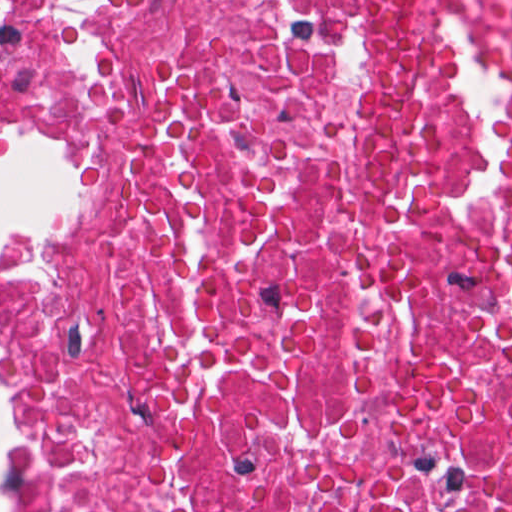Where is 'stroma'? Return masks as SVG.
Returning <instances> with one entry per match:
<instances>
[{"label": "stroma", "instance_id": "35a3bbf8", "mask_svg": "<svg viewBox=\"0 0 512 512\" xmlns=\"http://www.w3.org/2000/svg\"><path fill=\"white\" fill-rule=\"evenodd\" d=\"M20 136H44L73 145L82 158V194L74 215L54 235L27 246H22L0 259V394L5 406L6 294L16 277L32 258L51 252L71 242L73 237L64 234L74 236L92 193V170L89 154L78 147L62 129L45 121L37 111L0 125V140ZM2 470L8 497V512H26L24 505V466L12 435L5 449Z\"/></svg>", "mask_w": 512, "mask_h": 512}]
</instances>
